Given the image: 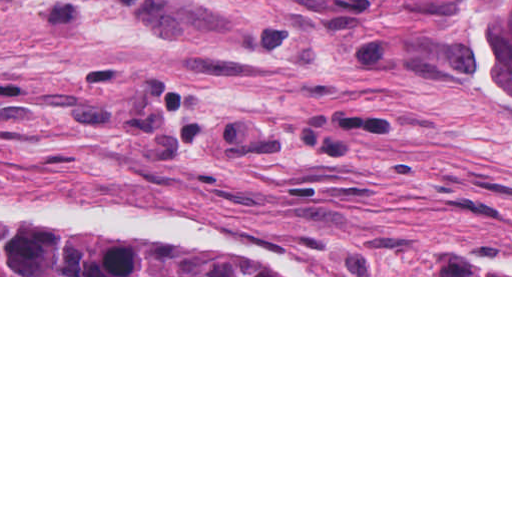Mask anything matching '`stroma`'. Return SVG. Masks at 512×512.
Here are the masks:
<instances>
[{"instance_id":"stroma-1","label":"stroma","mask_w":512,"mask_h":512,"mask_svg":"<svg viewBox=\"0 0 512 512\" xmlns=\"http://www.w3.org/2000/svg\"><path fill=\"white\" fill-rule=\"evenodd\" d=\"M512 277V93L458 0H0V229Z\"/></svg>"}]
</instances>
